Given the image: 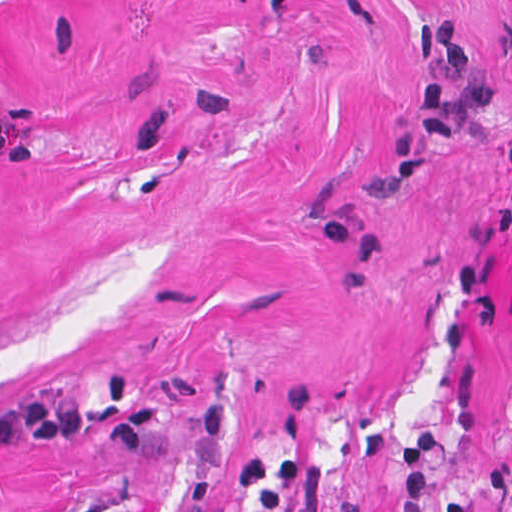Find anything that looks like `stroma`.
Listing matches in <instances>:
<instances>
[{
  "mask_svg": "<svg viewBox=\"0 0 512 512\" xmlns=\"http://www.w3.org/2000/svg\"><path fill=\"white\" fill-rule=\"evenodd\" d=\"M512 0H0V512H512Z\"/></svg>",
  "mask_w": 512,
  "mask_h": 512,
  "instance_id": "1",
  "label": "stroma"
}]
</instances>
